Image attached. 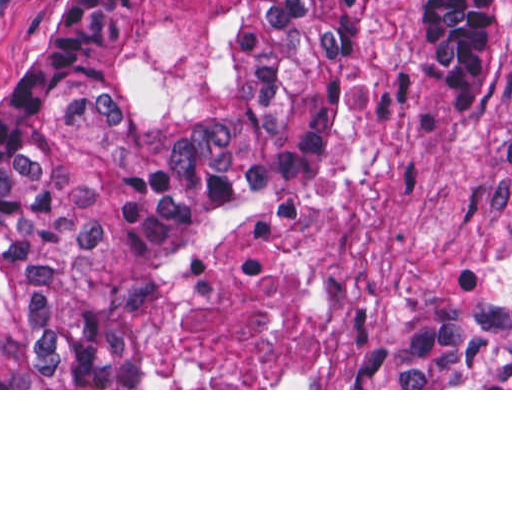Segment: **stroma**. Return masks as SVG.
Returning <instances> with one entry per match:
<instances>
[{
  "mask_svg": "<svg viewBox=\"0 0 512 512\" xmlns=\"http://www.w3.org/2000/svg\"><path fill=\"white\" fill-rule=\"evenodd\" d=\"M69 0H0V76ZM512 302V0H496L482 76L456 102L429 0H360L308 177L181 244L148 309L145 388H366V336L410 303Z\"/></svg>",
  "mask_w": 512,
  "mask_h": 512,
  "instance_id": "obj_1",
  "label": "stroma"
}]
</instances>
